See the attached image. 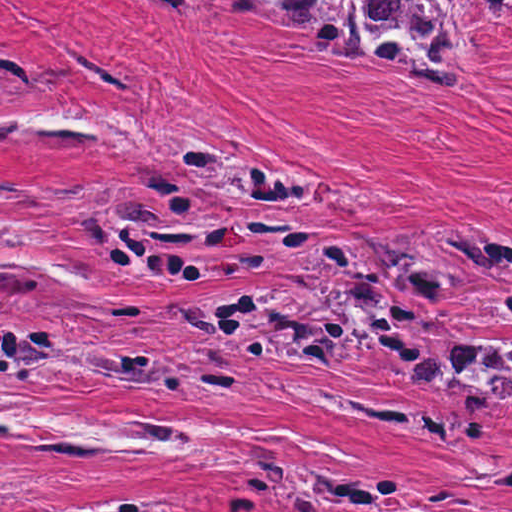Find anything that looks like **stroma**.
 <instances>
[{
    "mask_svg": "<svg viewBox=\"0 0 512 512\" xmlns=\"http://www.w3.org/2000/svg\"><path fill=\"white\" fill-rule=\"evenodd\" d=\"M445 1L460 80L420 98L397 73L329 60L223 0L187 23L151 0H0V512L142 493L170 494L165 512H238L231 497L259 480L255 444L285 467L387 474L512 509V406L403 382L381 355L339 375L230 346L247 374L232 406L78 376L92 339L142 344L171 364L186 348L225 346L167 303L291 285L323 244L478 224L512 250V31L485 0ZM1 47L38 65L35 91L1 92ZM158 134L311 176L289 208L209 192L230 211L311 226L310 239L283 264L207 281L143 284L87 263L76 224L131 184ZM1 310L48 342L41 379L1 377ZM1 407L273 436L207 444L225 463L1 446ZM250 500L246 512H300Z\"/></svg>",
    "mask_w": 512,
    "mask_h": 512,
    "instance_id": "1",
    "label": "stroma"
}]
</instances>
